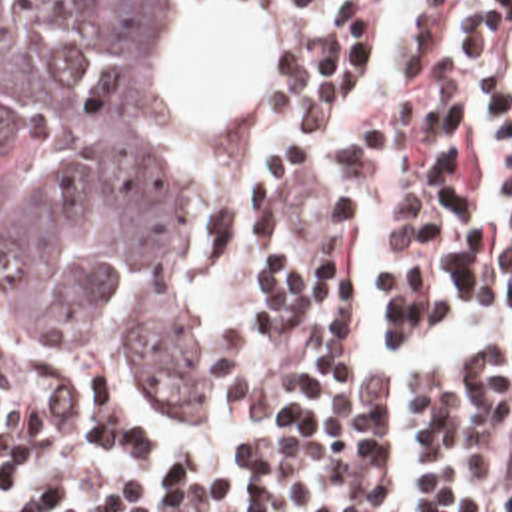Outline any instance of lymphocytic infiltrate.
I'll use <instances>...</instances> for the list:
<instances>
[{
    "label": "lymphocytic infiltrate",
    "instance_id": "lymphocytic-infiltrate-1",
    "mask_svg": "<svg viewBox=\"0 0 512 512\" xmlns=\"http://www.w3.org/2000/svg\"><path fill=\"white\" fill-rule=\"evenodd\" d=\"M277 37L247 107L227 237L199 313L219 417L243 453L187 461L137 491L105 483L5 512H379L391 489L399 373L351 367L367 337L359 203H379L395 343L471 309L512 313V0H415V45L387 101L359 113L379 0H239ZM421 512H512V347L421 379ZM79 439L161 449L143 423L97 417L0 355V481Z\"/></svg>",
    "mask_w": 512,
    "mask_h": 512
}]
</instances>
